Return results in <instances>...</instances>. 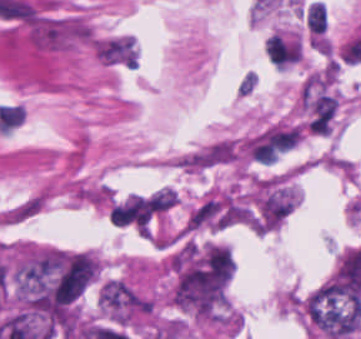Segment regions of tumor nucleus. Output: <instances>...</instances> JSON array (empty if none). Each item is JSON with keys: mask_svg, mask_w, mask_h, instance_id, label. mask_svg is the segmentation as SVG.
Wrapping results in <instances>:
<instances>
[{"mask_svg": "<svg viewBox=\"0 0 361 339\" xmlns=\"http://www.w3.org/2000/svg\"><path fill=\"white\" fill-rule=\"evenodd\" d=\"M301 310L323 336L353 339L361 324V294L333 278L313 289Z\"/></svg>", "mask_w": 361, "mask_h": 339, "instance_id": "2f306a5c", "label": "tumor nucleus"}, {"mask_svg": "<svg viewBox=\"0 0 361 339\" xmlns=\"http://www.w3.org/2000/svg\"><path fill=\"white\" fill-rule=\"evenodd\" d=\"M94 50L108 62L134 65L135 48L129 36H115L94 41Z\"/></svg>", "mask_w": 361, "mask_h": 339, "instance_id": "8643909e", "label": "tumor nucleus"}]
</instances>
